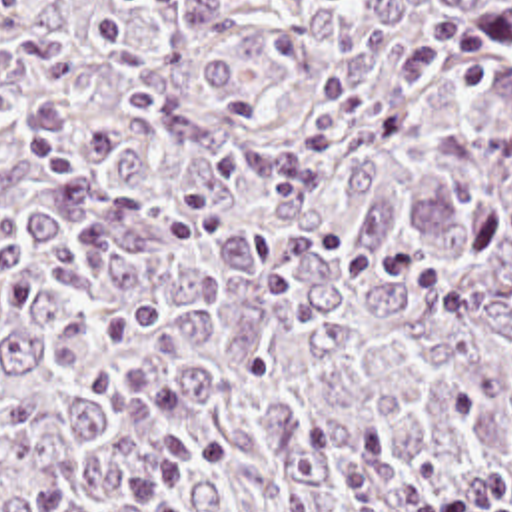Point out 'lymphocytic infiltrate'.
Segmentation results:
<instances>
[{
	"label": "lymphocytic infiltrate",
	"mask_w": 512,
	"mask_h": 512,
	"mask_svg": "<svg viewBox=\"0 0 512 512\" xmlns=\"http://www.w3.org/2000/svg\"><path fill=\"white\" fill-rule=\"evenodd\" d=\"M414 512H511L509 470L460 472L424 496Z\"/></svg>",
	"instance_id": "f902f5d3"
}]
</instances>
